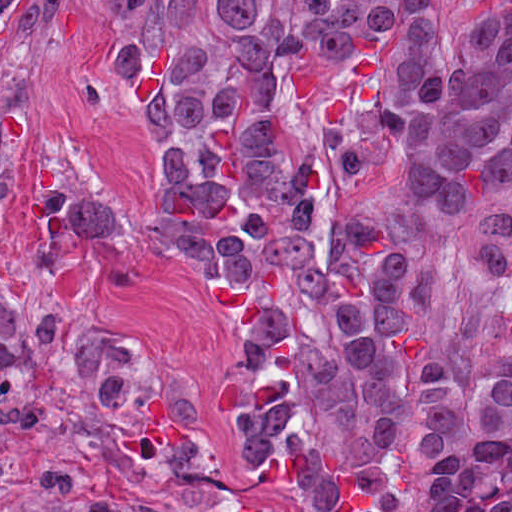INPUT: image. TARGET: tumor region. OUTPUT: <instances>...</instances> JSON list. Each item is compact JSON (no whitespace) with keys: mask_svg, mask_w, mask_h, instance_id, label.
Wrapping results in <instances>:
<instances>
[{"mask_svg":"<svg viewBox=\"0 0 512 512\" xmlns=\"http://www.w3.org/2000/svg\"><path fill=\"white\" fill-rule=\"evenodd\" d=\"M110 1L129 12L141 0ZM431 1L173 0L113 52L115 81L148 128ZM15 2L0 0V27Z\"/></svg>","mask_w":512,"mask_h":512,"instance_id":"obj_1","label":"tumor region"}]
</instances>
